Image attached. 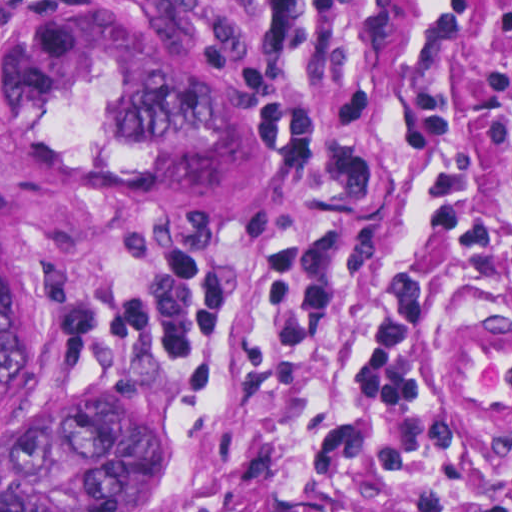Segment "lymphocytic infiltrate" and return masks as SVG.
<instances>
[{"label": "lymphocytic infiltrate", "mask_w": 512, "mask_h": 512, "mask_svg": "<svg viewBox=\"0 0 512 512\" xmlns=\"http://www.w3.org/2000/svg\"><path fill=\"white\" fill-rule=\"evenodd\" d=\"M459 83L488 93L494 139L512 145V65L395 99L405 158L430 223L462 263L490 282L511 270L512 253L455 142ZM380 191L381 178L359 145L357 116L316 154L312 197L283 234L238 251L143 254L75 285L60 304L67 324L105 349L180 354L204 369L227 424L188 512H223L212 504L211 486L236 444L218 379L231 260L240 253L262 274L271 317L291 325L323 323L343 301L347 280L370 261L368 219ZM430 296L423 278L390 276L362 305L358 351L341 382L340 420L280 512H314L311 493L326 480L346 489L404 484L415 491L421 512H512V479L470 468L444 417L443 401L457 399L434 371L436 345L424 329Z\"/></svg>", "instance_id": "lymphocytic-infiltrate-1"}]
</instances>
